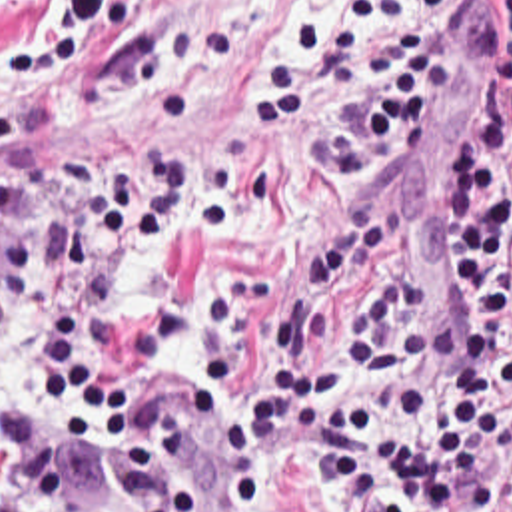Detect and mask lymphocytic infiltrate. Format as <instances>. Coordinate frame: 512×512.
Here are the masks:
<instances>
[{
  "label": "lymphocytic infiltrate",
  "mask_w": 512,
  "mask_h": 512,
  "mask_svg": "<svg viewBox=\"0 0 512 512\" xmlns=\"http://www.w3.org/2000/svg\"><path fill=\"white\" fill-rule=\"evenodd\" d=\"M449 0H347L339 13L279 29L291 59L259 51L253 113L273 133L329 93L359 29L391 27L397 63L345 97L331 119L333 173H365L407 153L485 43L489 69L453 143V275L465 297L459 329L431 313L425 271L385 245L373 219L339 225L305 269L307 301L353 271L385 273L347 325V379L327 363L239 394L259 434L223 424L231 470L213 512H251L253 496L289 476L333 484V512H495L512 494V0L499 31L477 17L407 19ZM16 173L0 163V225L14 213ZM265 221L255 173L239 159L185 149L112 163L90 145L68 151L54 183V241L14 227L0 243V333L24 319L58 392L92 416L110 404L133 359H171L189 341L185 303H161L112 327L114 299L173 235L245 247ZM211 375L137 388L112 410L110 452L137 512H199L177 468L217 434ZM80 442L30 400L0 420V512H66L80 488Z\"/></svg>",
  "instance_id": "lymphocytic-infiltrate-1"
}]
</instances>
